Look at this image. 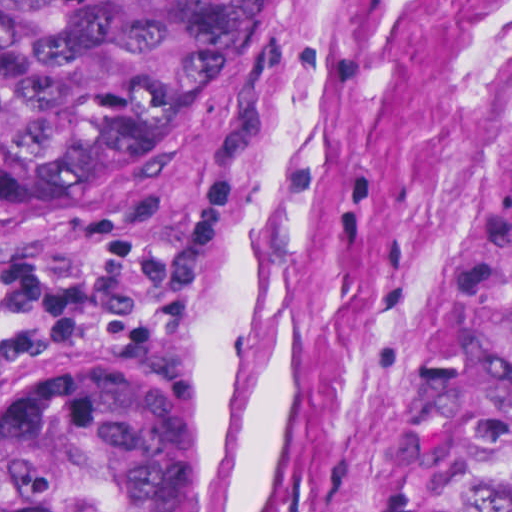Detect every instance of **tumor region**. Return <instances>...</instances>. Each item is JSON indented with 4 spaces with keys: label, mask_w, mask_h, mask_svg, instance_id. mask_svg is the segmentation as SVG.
Wrapping results in <instances>:
<instances>
[{
    "label": "tumor region",
    "mask_w": 512,
    "mask_h": 512,
    "mask_svg": "<svg viewBox=\"0 0 512 512\" xmlns=\"http://www.w3.org/2000/svg\"><path fill=\"white\" fill-rule=\"evenodd\" d=\"M293 0H0V232L54 228L274 63ZM0 512H183V391L142 362L0 381ZM405 512H512V182L443 329Z\"/></svg>",
    "instance_id": "1"
}]
</instances>
